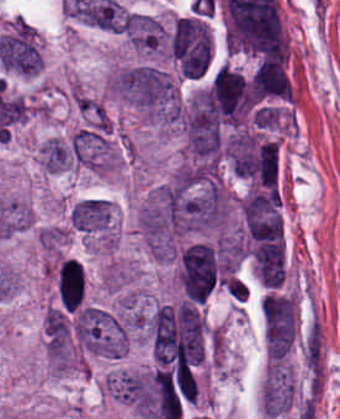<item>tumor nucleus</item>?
<instances>
[{
  "mask_svg": "<svg viewBox=\"0 0 340 419\" xmlns=\"http://www.w3.org/2000/svg\"><path fill=\"white\" fill-rule=\"evenodd\" d=\"M123 33L140 56H160L167 52V29L162 21L153 15L128 12Z\"/></svg>",
  "mask_w": 340,
  "mask_h": 419,
  "instance_id": "1",
  "label": "tumor nucleus"
},
{
  "mask_svg": "<svg viewBox=\"0 0 340 419\" xmlns=\"http://www.w3.org/2000/svg\"><path fill=\"white\" fill-rule=\"evenodd\" d=\"M44 325L52 338L65 341L68 334L67 320L60 310L49 306L46 309Z\"/></svg>",
  "mask_w": 340,
  "mask_h": 419,
  "instance_id": "2",
  "label": "tumor nucleus"
}]
</instances>
